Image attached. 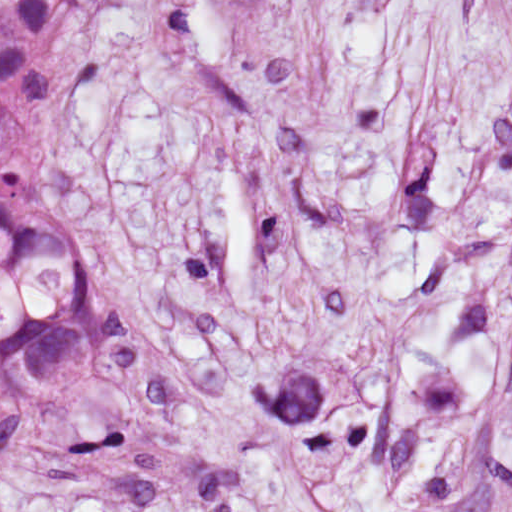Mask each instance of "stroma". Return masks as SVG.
<instances>
[{
  "label": "stroma",
  "mask_w": 512,
  "mask_h": 512,
  "mask_svg": "<svg viewBox=\"0 0 512 512\" xmlns=\"http://www.w3.org/2000/svg\"><path fill=\"white\" fill-rule=\"evenodd\" d=\"M67 152L101 355L0 512H512V0H107Z\"/></svg>",
  "instance_id": "stroma-1"
}]
</instances>
